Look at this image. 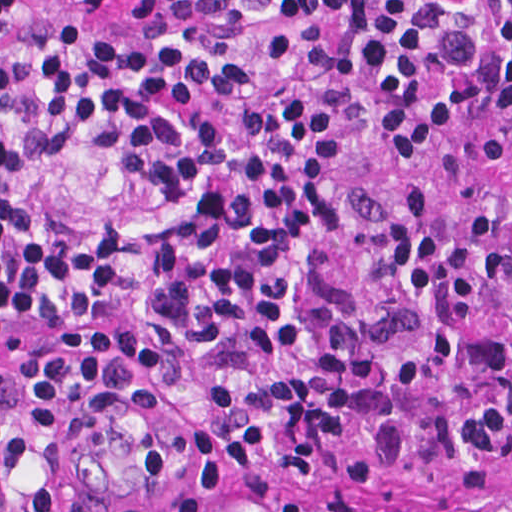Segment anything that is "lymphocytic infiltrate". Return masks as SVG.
<instances>
[{
	"label": "lymphocytic infiltrate",
	"mask_w": 512,
	"mask_h": 512,
	"mask_svg": "<svg viewBox=\"0 0 512 512\" xmlns=\"http://www.w3.org/2000/svg\"><path fill=\"white\" fill-rule=\"evenodd\" d=\"M26 0H0V41ZM286 24H342L375 84L383 157L450 146L479 107L512 105V0H269ZM51 158L91 148L127 160L184 219L150 248L153 316L219 353L251 331L269 353L316 348L300 244L335 222L325 185L338 117L283 100L231 131H198L192 103L251 98L252 61L180 41H134L102 22L44 46ZM372 277L341 296L322 354L210 395L189 474L210 488L149 498L84 484L86 441L133 381L113 356L56 355L0 395V512H219L232 490L295 478L358 489L454 470L512 450V181L439 223L402 189ZM124 230L51 236L0 125V308L24 320H108L121 299ZM335 512H451L346 501Z\"/></svg>",
	"instance_id": "lymphocytic-infiltrate-1"
}]
</instances>
